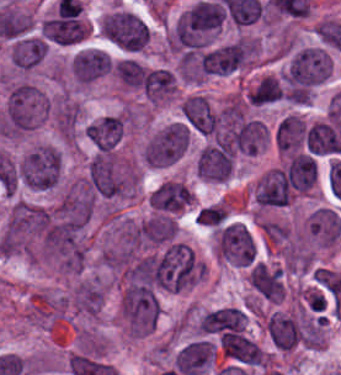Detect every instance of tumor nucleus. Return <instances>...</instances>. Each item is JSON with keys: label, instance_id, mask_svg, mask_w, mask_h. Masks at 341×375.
Instances as JSON below:
<instances>
[{"label": "tumor nucleus", "instance_id": "tumor-nucleus-21", "mask_svg": "<svg viewBox=\"0 0 341 375\" xmlns=\"http://www.w3.org/2000/svg\"><path fill=\"white\" fill-rule=\"evenodd\" d=\"M247 279L268 300L279 301L283 281L278 267L257 261Z\"/></svg>", "mask_w": 341, "mask_h": 375}, {"label": "tumor nucleus", "instance_id": "tumor-nucleus-12", "mask_svg": "<svg viewBox=\"0 0 341 375\" xmlns=\"http://www.w3.org/2000/svg\"><path fill=\"white\" fill-rule=\"evenodd\" d=\"M110 68L107 53L95 48H82L69 59V73L79 82H89L106 74Z\"/></svg>", "mask_w": 341, "mask_h": 375}, {"label": "tumor nucleus", "instance_id": "tumor-nucleus-4", "mask_svg": "<svg viewBox=\"0 0 341 375\" xmlns=\"http://www.w3.org/2000/svg\"><path fill=\"white\" fill-rule=\"evenodd\" d=\"M51 218V212L43 206L15 201L0 239L5 247H21L41 235Z\"/></svg>", "mask_w": 341, "mask_h": 375}, {"label": "tumor nucleus", "instance_id": "tumor-nucleus-17", "mask_svg": "<svg viewBox=\"0 0 341 375\" xmlns=\"http://www.w3.org/2000/svg\"><path fill=\"white\" fill-rule=\"evenodd\" d=\"M307 229L313 239L329 247L341 235V215L326 207H319L310 213Z\"/></svg>", "mask_w": 341, "mask_h": 375}, {"label": "tumor nucleus", "instance_id": "tumor-nucleus-11", "mask_svg": "<svg viewBox=\"0 0 341 375\" xmlns=\"http://www.w3.org/2000/svg\"><path fill=\"white\" fill-rule=\"evenodd\" d=\"M185 123L201 134H212L220 129L218 117L206 96L193 94L182 102Z\"/></svg>", "mask_w": 341, "mask_h": 375}, {"label": "tumor nucleus", "instance_id": "tumor-nucleus-16", "mask_svg": "<svg viewBox=\"0 0 341 375\" xmlns=\"http://www.w3.org/2000/svg\"><path fill=\"white\" fill-rule=\"evenodd\" d=\"M122 131L121 116L108 114L90 121L84 133L96 149L111 150L120 140Z\"/></svg>", "mask_w": 341, "mask_h": 375}, {"label": "tumor nucleus", "instance_id": "tumor-nucleus-3", "mask_svg": "<svg viewBox=\"0 0 341 375\" xmlns=\"http://www.w3.org/2000/svg\"><path fill=\"white\" fill-rule=\"evenodd\" d=\"M85 181L94 196H120L131 189L132 172L109 152L96 151L88 163Z\"/></svg>", "mask_w": 341, "mask_h": 375}, {"label": "tumor nucleus", "instance_id": "tumor-nucleus-25", "mask_svg": "<svg viewBox=\"0 0 341 375\" xmlns=\"http://www.w3.org/2000/svg\"><path fill=\"white\" fill-rule=\"evenodd\" d=\"M305 131V123L294 114L280 118L275 130V141L278 149L291 148L300 143Z\"/></svg>", "mask_w": 341, "mask_h": 375}, {"label": "tumor nucleus", "instance_id": "tumor-nucleus-14", "mask_svg": "<svg viewBox=\"0 0 341 375\" xmlns=\"http://www.w3.org/2000/svg\"><path fill=\"white\" fill-rule=\"evenodd\" d=\"M191 194L192 191L186 183L168 179L150 194V203L158 212L168 215L187 207Z\"/></svg>", "mask_w": 341, "mask_h": 375}, {"label": "tumor nucleus", "instance_id": "tumor-nucleus-18", "mask_svg": "<svg viewBox=\"0 0 341 375\" xmlns=\"http://www.w3.org/2000/svg\"><path fill=\"white\" fill-rule=\"evenodd\" d=\"M46 54V40L36 35H22L11 42L10 61L17 70H28Z\"/></svg>", "mask_w": 341, "mask_h": 375}, {"label": "tumor nucleus", "instance_id": "tumor-nucleus-13", "mask_svg": "<svg viewBox=\"0 0 341 375\" xmlns=\"http://www.w3.org/2000/svg\"><path fill=\"white\" fill-rule=\"evenodd\" d=\"M213 358L209 341L202 338L184 343L174 354V368L185 375H196L205 369Z\"/></svg>", "mask_w": 341, "mask_h": 375}, {"label": "tumor nucleus", "instance_id": "tumor-nucleus-5", "mask_svg": "<svg viewBox=\"0 0 341 375\" xmlns=\"http://www.w3.org/2000/svg\"><path fill=\"white\" fill-rule=\"evenodd\" d=\"M121 312L133 334H144L158 316L159 298L152 288L129 281L122 292Z\"/></svg>", "mask_w": 341, "mask_h": 375}, {"label": "tumor nucleus", "instance_id": "tumor-nucleus-26", "mask_svg": "<svg viewBox=\"0 0 341 375\" xmlns=\"http://www.w3.org/2000/svg\"><path fill=\"white\" fill-rule=\"evenodd\" d=\"M79 119V109L73 102H62L57 113V123L59 131L63 136H72Z\"/></svg>", "mask_w": 341, "mask_h": 375}, {"label": "tumor nucleus", "instance_id": "tumor-nucleus-10", "mask_svg": "<svg viewBox=\"0 0 341 375\" xmlns=\"http://www.w3.org/2000/svg\"><path fill=\"white\" fill-rule=\"evenodd\" d=\"M265 330L274 348L290 349L302 342L304 328L296 315L273 311L269 314Z\"/></svg>", "mask_w": 341, "mask_h": 375}, {"label": "tumor nucleus", "instance_id": "tumor-nucleus-20", "mask_svg": "<svg viewBox=\"0 0 341 375\" xmlns=\"http://www.w3.org/2000/svg\"><path fill=\"white\" fill-rule=\"evenodd\" d=\"M178 225L168 215H154L133 228V238L143 244H163L173 239Z\"/></svg>", "mask_w": 341, "mask_h": 375}, {"label": "tumor nucleus", "instance_id": "tumor-nucleus-7", "mask_svg": "<svg viewBox=\"0 0 341 375\" xmlns=\"http://www.w3.org/2000/svg\"><path fill=\"white\" fill-rule=\"evenodd\" d=\"M246 46L243 41L217 43L208 46L191 63L194 75L232 73L245 60Z\"/></svg>", "mask_w": 341, "mask_h": 375}, {"label": "tumor nucleus", "instance_id": "tumor-nucleus-9", "mask_svg": "<svg viewBox=\"0 0 341 375\" xmlns=\"http://www.w3.org/2000/svg\"><path fill=\"white\" fill-rule=\"evenodd\" d=\"M196 175L209 181H223L231 171V148L214 142L205 146L196 157Z\"/></svg>", "mask_w": 341, "mask_h": 375}, {"label": "tumor nucleus", "instance_id": "tumor-nucleus-19", "mask_svg": "<svg viewBox=\"0 0 341 375\" xmlns=\"http://www.w3.org/2000/svg\"><path fill=\"white\" fill-rule=\"evenodd\" d=\"M203 328L247 335L246 311L236 306H222L209 310L203 317Z\"/></svg>", "mask_w": 341, "mask_h": 375}, {"label": "tumor nucleus", "instance_id": "tumor-nucleus-15", "mask_svg": "<svg viewBox=\"0 0 341 375\" xmlns=\"http://www.w3.org/2000/svg\"><path fill=\"white\" fill-rule=\"evenodd\" d=\"M266 140L265 125L254 118L240 117L231 123V149L240 153H255Z\"/></svg>", "mask_w": 341, "mask_h": 375}, {"label": "tumor nucleus", "instance_id": "tumor-nucleus-2", "mask_svg": "<svg viewBox=\"0 0 341 375\" xmlns=\"http://www.w3.org/2000/svg\"><path fill=\"white\" fill-rule=\"evenodd\" d=\"M44 111V96L41 91L19 81L11 86L4 112L5 136L21 137L39 120Z\"/></svg>", "mask_w": 341, "mask_h": 375}, {"label": "tumor nucleus", "instance_id": "tumor-nucleus-6", "mask_svg": "<svg viewBox=\"0 0 341 375\" xmlns=\"http://www.w3.org/2000/svg\"><path fill=\"white\" fill-rule=\"evenodd\" d=\"M190 129L181 120L166 123L142 148L148 165H169L182 156L189 145Z\"/></svg>", "mask_w": 341, "mask_h": 375}, {"label": "tumor nucleus", "instance_id": "tumor-nucleus-8", "mask_svg": "<svg viewBox=\"0 0 341 375\" xmlns=\"http://www.w3.org/2000/svg\"><path fill=\"white\" fill-rule=\"evenodd\" d=\"M217 249L226 259L248 265L257 252V244L246 226L231 222L218 232Z\"/></svg>", "mask_w": 341, "mask_h": 375}, {"label": "tumor nucleus", "instance_id": "tumor-nucleus-24", "mask_svg": "<svg viewBox=\"0 0 341 375\" xmlns=\"http://www.w3.org/2000/svg\"><path fill=\"white\" fill-rule=\"evenodd\" d=\"M283 96V84L276 77L264 75L248 92L247 101L252 106H263L279 101Z\"/></svg>", "mask_w": 341, "mask_h": 375}, {"label": "tumor nucleus", "instance_id": "tumor-nucleus-1", "mask_svg": "<svg viewBox=\"0 0 341 375\" xmlns=\"http://www.w3.org/2000/svg\"><path fill=\"white\" fill-rule=\"evenodd\" d=\"M223 24V7L216 1L198 0L175 21L179 48H199L213 38Z\"/></svg>", "mask_w": 341, "mask_h": 375}, {"label": "tumor nucleus", "instance_id": "tumor-nucleus-22", "mask_svg": "<svg viewBox=\"0 0 341 375\" xmlns=\"http://www.w3.org/2000/svg\"><path fill=\"white\" fill-rule=\"evenodd\" d=\"M220 344L225 355L246 364H258L260 348L256 343L242 333L222 332Z\"/></svg>", "mask_w": 341, "mask_h": 375}, {"label": "tumor nucleus", "instance_id": "tumor-nucleus-23", "mask_svg": "<svg viewBox=\"0 0 341 375\" xmlns=\"http://www.w3.org/2000/svg\"><path fill=\"white\" fill-rule=\"evenodd\" d=\"M285 171L291 185L306 191L316 181L315 158L308 153L296 152L290 156Z\"/></svg>", "mask_w": 341, "mask_h": 375}]
</instances>
